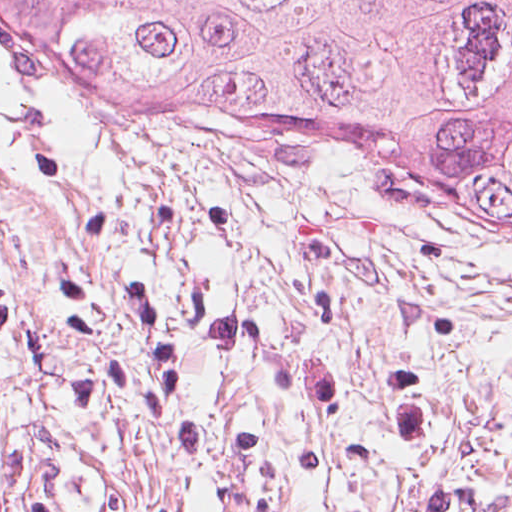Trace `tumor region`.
Here are the masks:
<instances>
[{
    "mask_svg": "<svg viewBox=\"0 0 512 512\" xmlns=\"http://www.w3.org/2000/svg\"><path fill=\"white\" fill-rule=\"evenodd\" d=\"M0 48L46 92L357 149L512 249V0H0Z\"/></svg>",
    "mask_w": 512,
    "mask_h": 512,
    "instance_id": "tumor-region-1",
    "label": "tumor region"
}]
</instances>
